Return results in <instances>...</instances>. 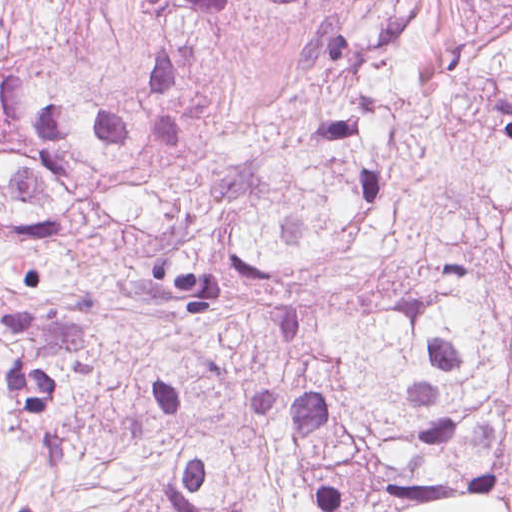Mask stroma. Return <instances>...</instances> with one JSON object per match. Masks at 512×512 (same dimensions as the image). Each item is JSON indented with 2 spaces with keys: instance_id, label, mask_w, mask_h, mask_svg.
I'll use <instances>...</instances> for the list:
<instances>
[{
  "instance_id": "35a3bbf8",
  "label": "stroma",
  "mask_w": 512,
  "mask_h": 512,
  "mask_svg": "<svg viewBox=\"0 0 512 512\" xmlns=\"http://www.w3.org/2000/svg\"><path fill=\"white\" fill-rule=\"evenodd\" d=\"M405 27L412 58L447 67H469L506 38L470 0H408ZM398 512H512V501H423Z\"/></svg>"
}]
</instances>
